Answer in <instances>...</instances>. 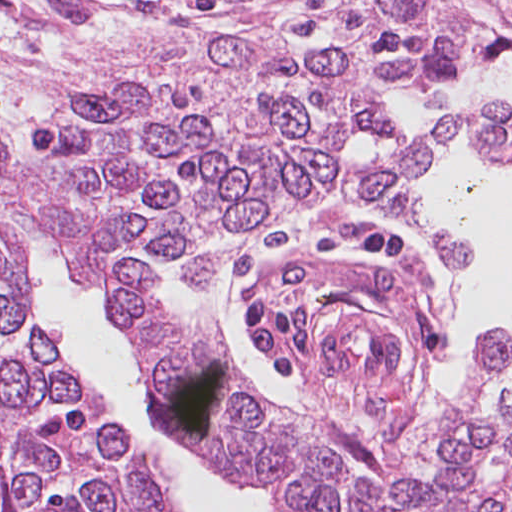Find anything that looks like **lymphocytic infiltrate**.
<instances>
[{
  "instance_id": "f902f5d3",
  "label": "lymphocytic infiltrate",
  "mask_w": 512,
  "mask_h": 512,
  "mask_svg": "<svg viewBox=\"0 0 512 512\" xmlns=\"http://www.w3.org/2000/svg\"><path fill=\"white\" fill-rule=\"evenodd\" d=\"M358 258L387 263L407 255V235L398 228L367 233L354 247ZM249 348L281 380L298 376L299 364L317 357L310 312L303 304L277 301L265 291L236 305Z\"/></svg>"
}]
</instances>
